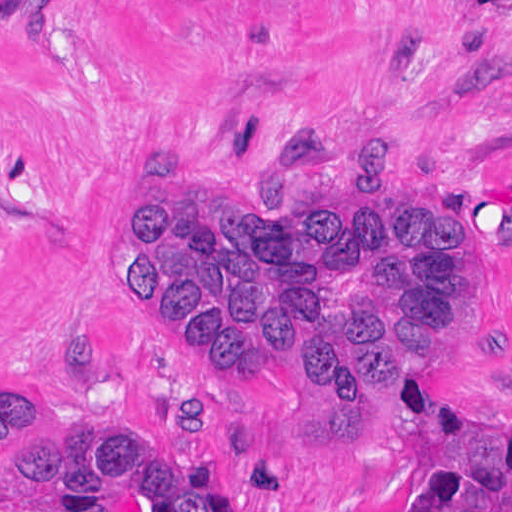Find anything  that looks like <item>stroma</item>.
<instances>
[{
  "instance_id": "35a3bbf8",
  "label": "stroma",
  "mask_w": 512,
  "mask_h": 512,
  "mask_svg": "<svg viewBox=\"0 0 512 512\" xmlns=\"http://www.w3.org/2000/svg\"><path fill=\"white\" fill-rule=\"evenodd\" d=\"M287 125L336 152L267 149ZM168 199L473 221L452 354L363 407L204 362L125 287ZM0 400L135 438L218 512H419V468L512 427V0H0Z\"/></svg>"
}]
</instances>
